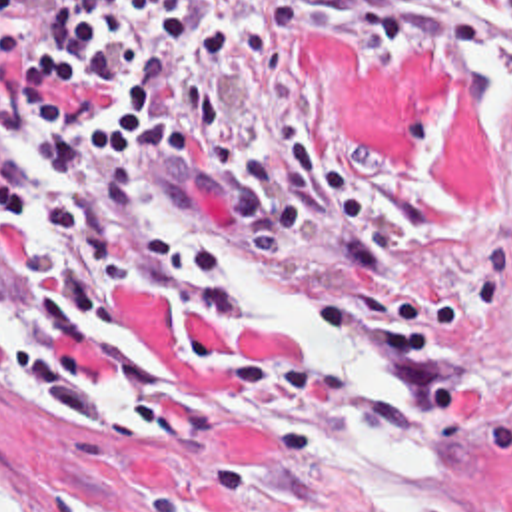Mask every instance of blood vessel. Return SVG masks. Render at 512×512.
I'll return each instance as SVG.
<instances>
[{"label": "blood vessel", "instance_id": "1", "mask_svg": "<svg viewBox=\"0 0 512 512\" xmlns=\"http://www.w3.org/2000/svg\"><path fill=\"white\" fill-rule=\"evenodd\" d=\"M70 0H0V17L6 23H44L62 13Z\"/></svg>", "mask_w": 512, "mask_h": 512}]
</instances>
